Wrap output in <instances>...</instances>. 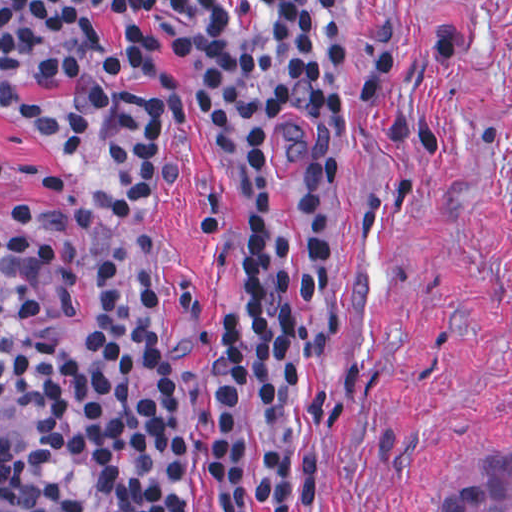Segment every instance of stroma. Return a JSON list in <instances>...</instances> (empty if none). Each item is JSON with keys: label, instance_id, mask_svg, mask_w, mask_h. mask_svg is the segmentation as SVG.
<instances>
[{"label": "stroma", "instance_id": "stroma-1", "mask_svg": "<svg viewBox=\"0 0 512 512\" xmlns=\"http://www.w3.org/2000/svg\"><path fill=\"white\" fill-rule=\"evenodd\" d=\"M274 0H94L65 68L0 66V239L45 262L86 323L77 214L121 170L120 27L155 28L174 75L172 179L149 269L206 502L209 335L240 298L242 217L264 189L306 243L298 460L319 512H441L479 449H512V0H336L359 126L356 193L310 204L262 145L257 68ZM28 426L15 437L13 452Z\"/></svg>", "mask_w": 512, "mask_h": 512}]
</instances>
